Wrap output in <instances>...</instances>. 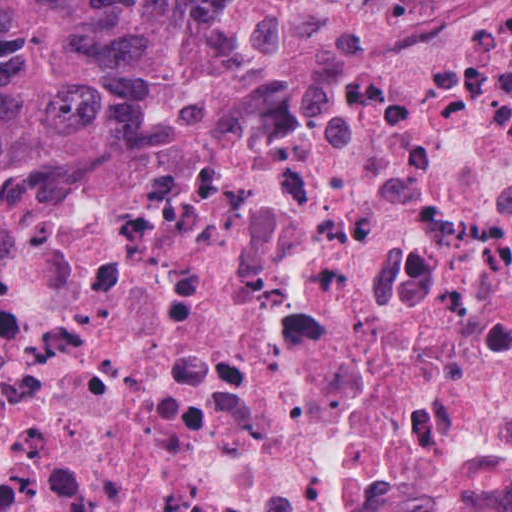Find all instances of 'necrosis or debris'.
<instances>
[{
  "instance_id": "1",
  "label": "necrosis or debris",
  "mask_w": 512,
  "mask_h": 512,
  "mask_svg": "<svg viewBox=\"0 0 512 512\" xmlns=\"http://www.w3.org/2000/svg\"><path fill=\"white\" fill-rule=\"evenodd\" d=\"M405 511L512 512V0H284L0 239V512Z\"/></svg>"
}]
</instances>
